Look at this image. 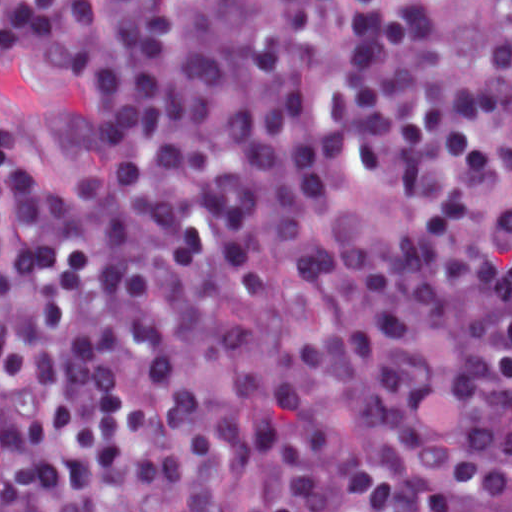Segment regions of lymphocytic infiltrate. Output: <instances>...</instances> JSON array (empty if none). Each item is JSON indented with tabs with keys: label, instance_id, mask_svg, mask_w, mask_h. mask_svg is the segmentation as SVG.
Listing matches in <instances>:
<instances>
[{
	"label": "lymphocytic infiltrate",
	"instance_id": "1",
	"mask_svg": "<svg viewBox=\"0 0 512 512\" xmlns=\"http://www.w3.org/2000/svg\"><path fill=\"white\" fill-rule=\"evenodd\" d=\"M1 512H512V95L449 0H1Z\"/></svg>",
	"mask_w": 512,
	"mask_h": 512
}]
</instances>
